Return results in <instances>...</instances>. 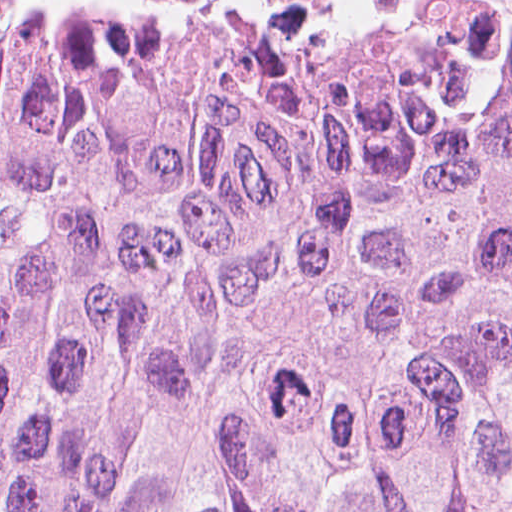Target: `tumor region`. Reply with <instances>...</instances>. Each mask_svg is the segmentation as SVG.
I'll list each match as a JSON object with an SVG mask.
<instances>
[{
	"label": "tumor region",
	"mask_w": 512,
	"mask_h": 512,
	"mask_svg": "<svg viewBox=\"0 0 512 512\" xmlns=\"http://www.w3.org/2000/svg\"><path fill=\"white\" fill-rule=\"evenodd\" d=\"M0 512H512V0H0Z\"/></svg>",
	"instance_id": "obj_1"
}]
</instances>
